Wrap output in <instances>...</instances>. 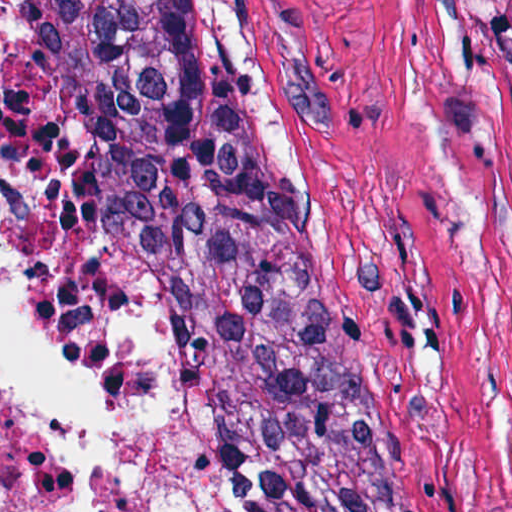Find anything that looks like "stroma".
I'll return each mask as SVG.
<instances>
[{"instance_id": "stroma-1", "label": "stroma", "mask_w": 512, "mask_h": 512, "mask_svg": "<svg viewBox=\"0 0 512 512\" xmlns=\"http://www.w3.org/2000/svg\"><path fill=\"white\" fill-rule=\"evenodd\" d=\"M149 1L248 82L298 226L432 464L512 512V0H0V248L24 288V139L65 38Z\"/></svg>"}]
</instances>
